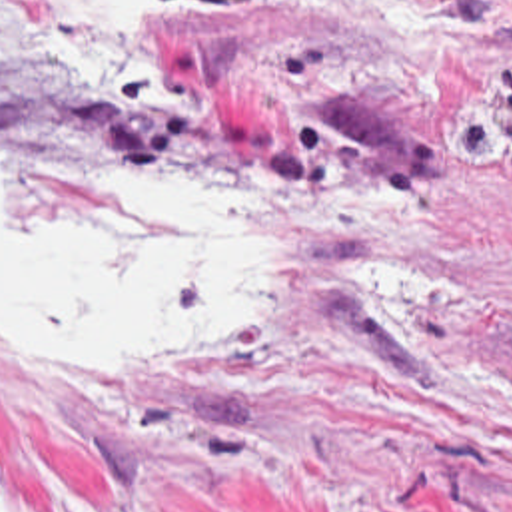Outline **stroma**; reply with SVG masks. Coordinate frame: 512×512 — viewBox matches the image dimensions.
Masks as SVG:
<instances>
[{"label":"stroma","mask_w":512,"mask_h":512,"mask_svg":"<svg viewBox=\"0 0 512 512\" xmlns=\"http://www.w3.org/2000/svg\"><path fill=\"white\" fill-rule=\"evenodd\" d=\"M90 74L0 0V173H225L261 291L177 353H0V512H512V0H149Z\"/></svg>","instance_id":"stroma-1"}]
</instances>
